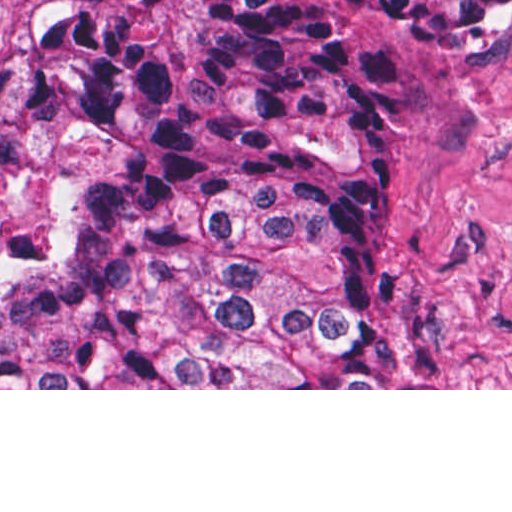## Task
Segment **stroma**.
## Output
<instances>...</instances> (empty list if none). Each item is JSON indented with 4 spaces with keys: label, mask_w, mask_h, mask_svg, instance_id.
I'll return each instance as SVG.
<instances>
[{
    "label": "stroma",
    "mask_w": 512,
    "mask_h": 512,
    "mask_svg": "<svg viewBox=\"0 0 512 512\" xmlns=\"http://www.w3.org/2000/svg\"><path fill=\"white\" fill-rule=\"evenodd\" d=\"M338 16L330 0H306ZM198 0H0V301L61 261L107 163L47 108L22 62L37 13L124 20L167 62L184 58ZM349 32L399 65L396 138L378 198V317L418 388L0 390H512V48H427L366 9Z\"/></svg>",
    "instance_id": "stroma-1"
}]
</instances>
